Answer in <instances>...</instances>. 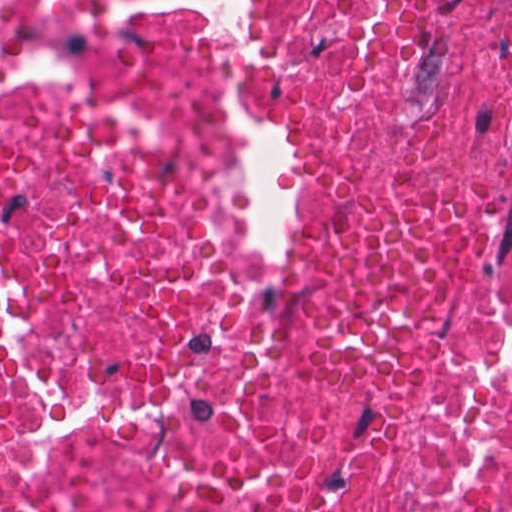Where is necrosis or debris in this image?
<instances>
[{
	"label": "necrosis or debris",
	"instance_id": "obj_1",
	"mask_svg": "<svg viewBox=\"0 0 512 512\" xmlns=\"http://www.w3.org/2000/svg\"><path fill=\"white\" fill-rule=\"evenodd\" d=\"M0 512H512V0H0Z\"/></svg>",
	"mask_w": 512,
	"mask_h": 512
}]
</instances>
